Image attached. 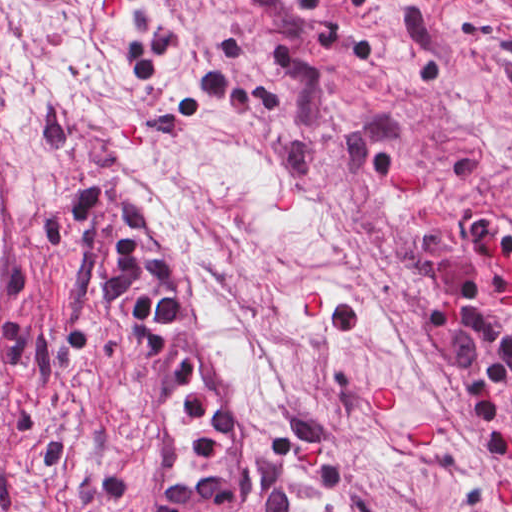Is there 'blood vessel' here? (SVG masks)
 Returning <instances> with one entry per match:
<instances>
[{
    "label": "blood vessel",
    "mask_w": 512,
    "mask_h": 512,
    "mask_svg": "<svg viewBox=\"0 0 512 512\" xmlns=\"http://www.w3.org/2000/svg\"><path fill=\"white\" fill-rule=\"evenodd\" d=\"M91 215L74 309L138 512H242L238 428L208 299L129 192ZM45 156L0 98V426L40 242Z\"/></svg>",
    "instance_id": "8fb6f2fc"
}]
</instances>
